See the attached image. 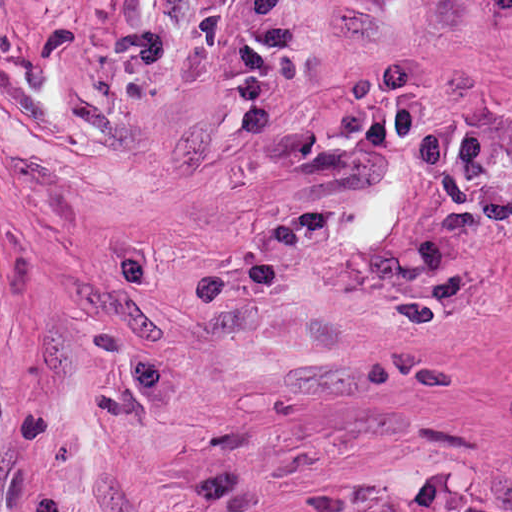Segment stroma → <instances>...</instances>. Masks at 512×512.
<instances>
[{
	"label": "stroma",
	"instance_id": "1",
	"mask_svg": "<svg viewBox=\"0 0 512 512\" xmlns=\"http://www.w3.org/2000/svg\"><path fill=\"white\" fill-rule=\"evenodd\" d=\"M384 512H512V118Z\"/></svg>",
	"mask_w": 512,
	"mask_h": 512
}]
</instances>
